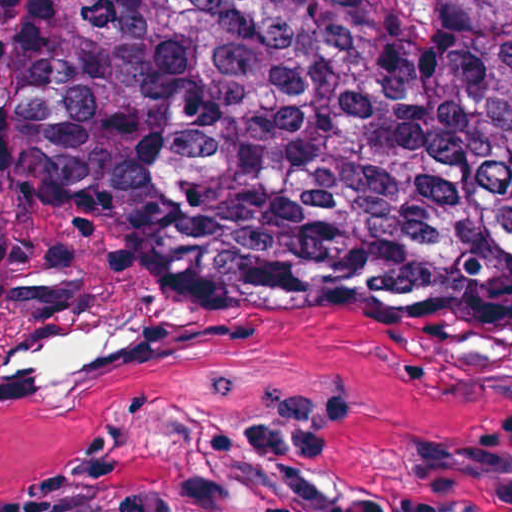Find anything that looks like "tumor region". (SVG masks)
Wrapping results in <instances>:
<instances>
[{
	"label": "tumor region",
	"instance_id": "tumor-region-1",
	"mask_svg": "<svg viewBox=\"0 0 512 512\" xmlns=\"http://www.w3.org/2000/svg\"><path fill=\"white\" fill-rule=\"evenodd\" d=\"M48 202L512 249V0H0V223Z\"/></svg>",
	"mask_w": 512,
	"mask_h": 512
}]
</instances>
